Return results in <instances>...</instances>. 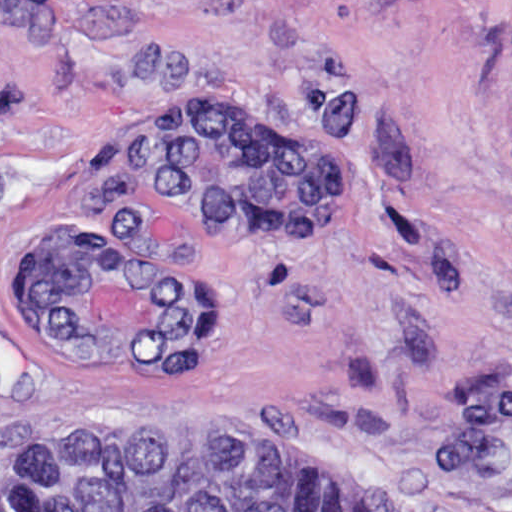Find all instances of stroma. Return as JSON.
<instances>
[{"label": "stroma", "instance_id": "obj_1", "mask_svg": "<svg viewBox=\"0 0 512 512\" xmlns=\"http://www.w3.org/2000/svg\"><path fill=\"white\" fill-rule=\"evenodd\" d=\"M204 91L296 128L330 230L233 246L132 172L138 126ZM50 220L203 278L204 362L60 359L19 289ZM61 431L242 439L373 512H512V0H0V478Z\"/></svg>", "mask_w": 512, "mask_h": 512}]
</instances>
